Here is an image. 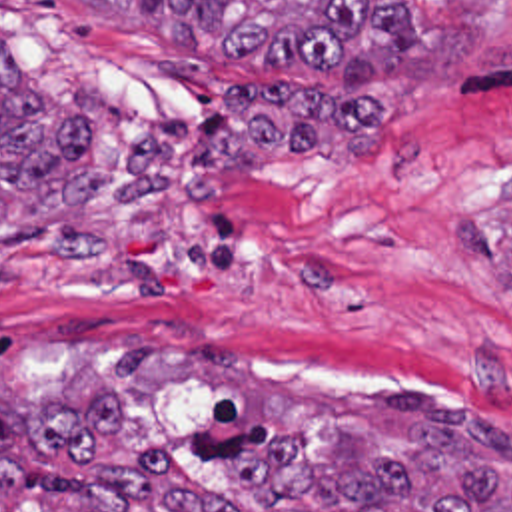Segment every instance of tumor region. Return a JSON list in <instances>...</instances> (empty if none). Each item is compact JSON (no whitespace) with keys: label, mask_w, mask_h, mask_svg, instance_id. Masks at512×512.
I'll list each match as a JSON object with an SVG mask.
<instances>
[{"label":"tumor region","mask_w":512,"mask_h":512,"mask_svg":"<svg viewBox=\"0 0 512 512\" xmlns=\"http://www.w3.org/2000/svg\"><path fill=\"white\" fill-rule=\"evenodd\" d=\"M178 46L280 72H334L340 84L411 64L415 20L401 0H94ZM94 128L64 94L26 74L0 44V248L62 234L100 250ZM512 284V248L509 250ZM411 413L413 435L385 449L375 431L332 423L316 461L300 433L238 467L236 491L288 512H512V427L479 403L427 391L377 393ZM493 419V421H491ZM0 512L2 511L0 509ZM22 512H240L192 479L162 445L104 463L90 493Z\"/></svg>","instance_id":"1"}]
</instances>
